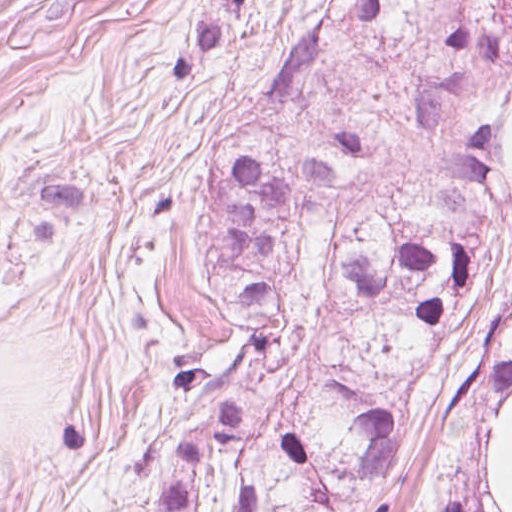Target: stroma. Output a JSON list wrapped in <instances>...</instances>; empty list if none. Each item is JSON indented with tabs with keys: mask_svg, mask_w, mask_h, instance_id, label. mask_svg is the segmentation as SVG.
<instances>
[{
	"mask_svg": "<svg viewBox=\"0 0 512 512\" xmlns=\"http://www.w3.org/2000/svg\"><path fill=\"white\" fill-rule=\"evenodd\" d=\"M216 0H0V512H156L172 417L243 334L193 241L219 143L259 172L357 130L347 185L308 212L289 290L311 309L352 231L404 195L446 0H239L184 80L138 95ZM329 20L313 102L225 107ZM417 472L393 512L425 493Z\"/></svg>",
	"mask_w": 512,
	"mask_h": 512,
	"instance_id": "stroma-1",
	"label": "stroma"
}]
</instances>
